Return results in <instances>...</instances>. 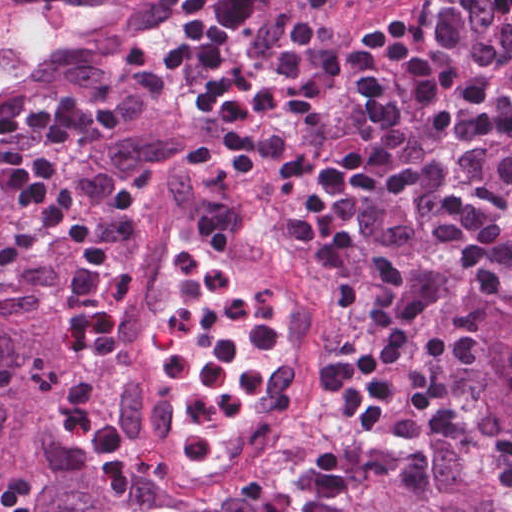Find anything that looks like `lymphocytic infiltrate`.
Instances as JSON below:
<instances>
[{
	"label": "lymphocytic infiltrate",
	"instance_id": "lymphocytic-infiltrate-1",
	"mask_svg": "<svg viewBox=\"0 0 512 512\" xmlns=\"http://www.w3.org/2000/svg\"><path fill=\"white\" fill-rule=\"evenodd\" d=\"M449 0L389 31L381 48L400 71L388 141L408 84L431 142L389 164L371 153L382 133L378 49L327 0H169L144 28V51L167 110L236 157L250 159L281 195L289 229L338 270L359 261L372 209L413 192L437 205L431 243L480 292L512 276V225L439 174L463 118L500 147L497 178L512 195V100L485 77L490 67L458 57L469 39L512 17V0ZM118 128L115 115L67 96L0 109V274L52 239H69L75 268L63 307L67 338L93 354L112 351L125 326L135 238L108 239L79 194L51 168ZM384 144V146H385ZM374 394L400 448L426 475L429 439L465 442L453 374L482 347L486 313L456 304L421 328L392 286L363 283ZM0 512H34L28 496L0 485Z\"/></svg>",
	"mask_w": 512,
	"mask_h": 512
}]
</instances>
